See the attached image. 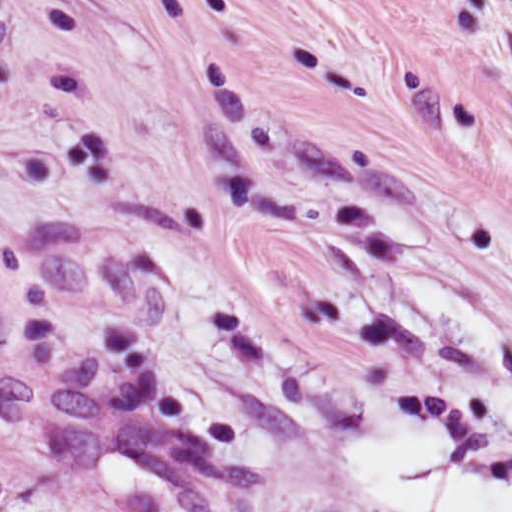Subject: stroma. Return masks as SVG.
Returning a JSON list of instances; mask_svg holds the SVG:
<instances>
[{
  "instance_id": "stroma-1",
  "label": "stroma",
  "mask_w": 512,
  "mask_h": 512,
  "mask_svg": "<svg viewBox=\"0 0 512 512\" xmlns=\"http://www.w3.org/2000/svg\"><path fill=\"white\" fill-rule=\"evenodd\" d=\"M512 482V0H0V512H401Z\"/></svg>"
}]
</instances>
